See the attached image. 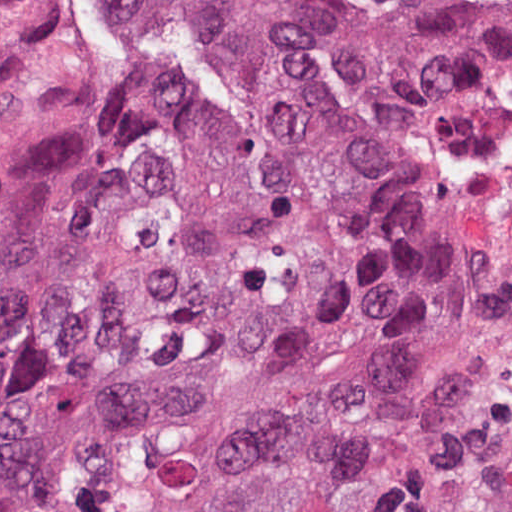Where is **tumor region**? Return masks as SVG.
Wrapping results in <instances>:
<instances>
[{"label": "tumor region", "instance_id": "obj_1", "mask_svg": "<svg viewBox=\"0 0 512 512\" xmlns=\"http://www.w3.org/2000/svg\"><path fill=\"white\" fill-rule=\"evenodd\" d=\"M511 155L512 0H169L164 126L34 328L17 512H479Z\"/></svg>", "mask_w": 512, "mask_h": 512}]
</instances>
